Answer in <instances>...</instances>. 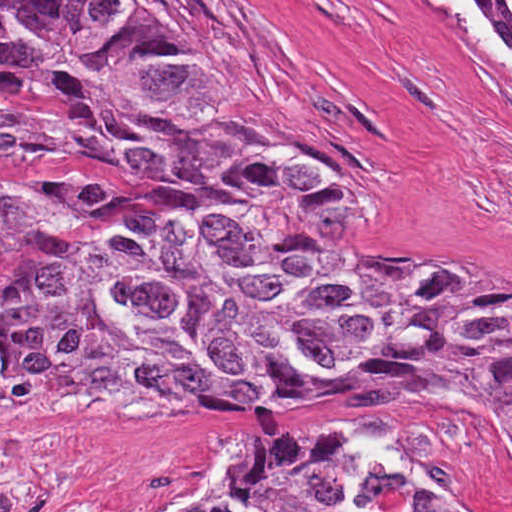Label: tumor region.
Listing matches in <instances>:
<instances>
[{"mask_svg":"<svg viewBox=\"0 0 512 512\" xmlns=\"http://www.w3.org/2000/svg\"><path fill=\"white\" fill-rule=\"evenodd\" d=\"M512 12V0H498ZM0 123L205 169L108 261L19 232L4 367L31 420L247 422L322 403L485 417L512 454V276L394 273L295 229L310 174L234 114L159 0H0ZM459 512L335 424L248 451L178 512Z\"/></svg>","mask_w":512,"mask_h":512,"instance_id":"tumor-region-1","label":"tumor region"}]
</instances>
